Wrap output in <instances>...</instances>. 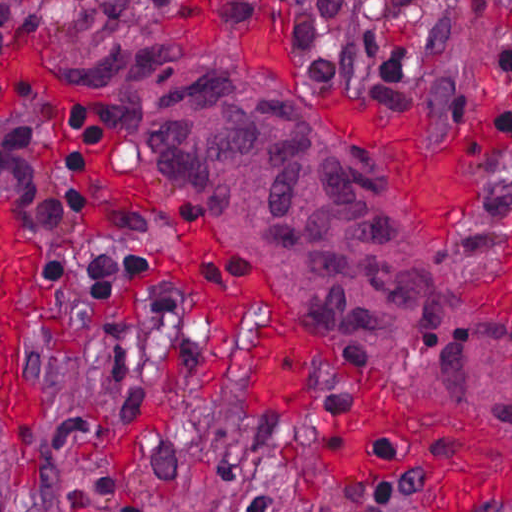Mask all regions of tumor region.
Masks as SVG:
<instances>
[{
	"mask_svg": "<svg viewBox=\"0 0 512 512\" xmlns=\"http://www.w3.org/2000/svg\"><path fill=\"white\" fill-rule=\"evenodd\" d=\"M42 27L38 8L0 0V60ZM72 77L84 95L135 111L153 186L277 280L319 349L512 438V322L438 276L397 186L358 147L235 65L131 48Z\"/></svg>",
	"mask_w": 512,
	"mask_h": 512,
	"instance_id": "obj_1",
	"label": "tumor region"
}]
</instances>
